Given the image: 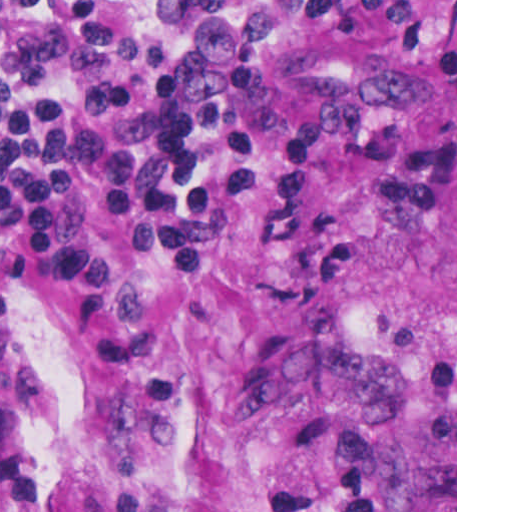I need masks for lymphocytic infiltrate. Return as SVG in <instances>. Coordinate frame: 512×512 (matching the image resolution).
<instances>
[{"label": "lymphocytic infiltrate", "mask_w": 512, "mask_h": 512, "mask_svg": "<svg viewBox=\"0 0 512 512\" xmlns=\"http://www.w3.org/2000/svg\"><path fill=\"white\" fill-rule=\"evenodd\" d=\"M294 32L455 68V0H0V301L50 286L74 358L153 359L152 305L102 251L97 212L177 276L203 273L219 206L189 150L195 128L226 146L243 191L256 147L276 142L261 225L290 223L313 145L365 118L336 105L288 121L257 58Z\"/></svg>", "instance_id": "f902f5d3"}]
</instances>
